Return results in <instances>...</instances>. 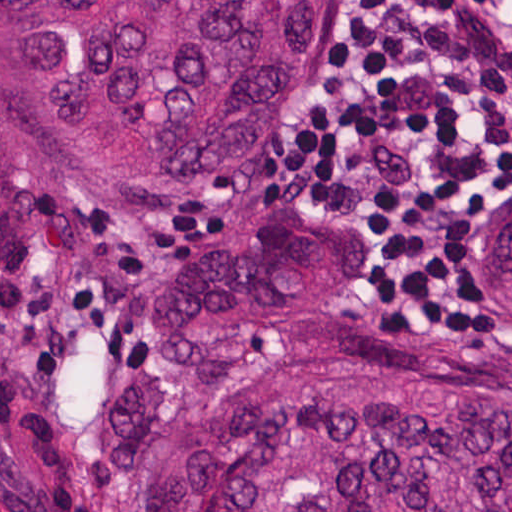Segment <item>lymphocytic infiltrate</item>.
I'll list each match as a JSON object with an SVG mask.
<instances>
[{
	"mask_svg": "<svg viewBox=\"0 0 512 512\" xmlns=\"http://www.w3.org/2000/svg\"><path fill=\"white\" fill-rule=\"evenodd\" d=\"M262 158L284 196L350 211L388 290L436 288L456 199L512 175V0H366Z\"/></svg>",
	"mask_w": 512,
	"mask_h": 512,
	"instance_id": "lymphocytic-infiltrate-1",
	"label": "lymphocytic infiltrate"
}]
</instances>
